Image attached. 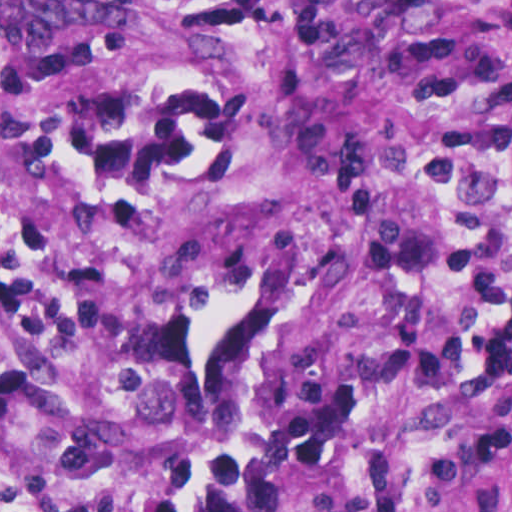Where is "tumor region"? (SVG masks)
<instances>
[{"mask_svg": "<svg viewBox=\"0 0 512 512\" xmlns=\"http://www.w3.org/2000/svg\"><path fill=\"white\" fill-rule=\"evenodd\" d=\"M126 0H1V57H79L121 27Z\"/></svg>", "mask_w": 512, "mask_h": 512, "instance_id": "e687c5a6", "label": "tumor region"}]
</instances>
